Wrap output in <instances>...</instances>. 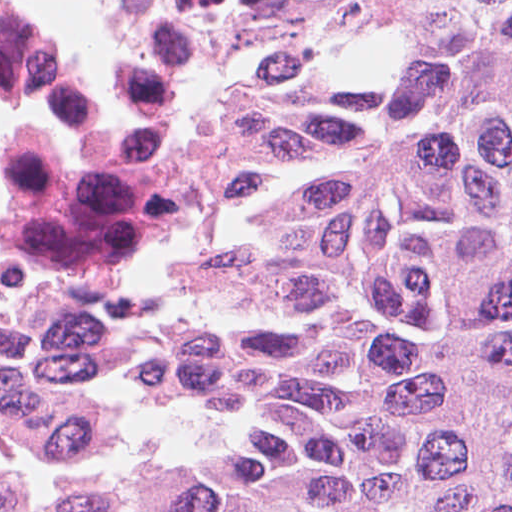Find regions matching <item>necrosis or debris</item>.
Returning a JSON list of instances; mask_svg holds the SVG:
<instances>
[{
  "instance_id": "necrosis-or-debris-1",
  "label": "necrosis or debris",
  "mask_w": 512,
  "mask_h": 512,
  "mask_svg": "<svg viewBox=\"0 0 512 512\" xmlns=\"http://www.w3.org/2000/svg\"><path fill=\"white\" fill-rule=\"evenodd\" d=\"M125 26L173 55L165 0H116ZM38 104L72 141L22 144L0 220V429L71 440L65 388L80 337L158 245L173 209V94L129 70L98 99L13 1L0 0V107ZM39 486L0 463V506Z\"/></svg>"
}]
</instances>
